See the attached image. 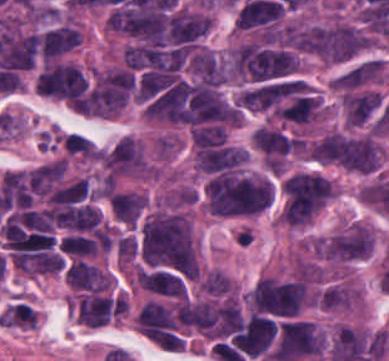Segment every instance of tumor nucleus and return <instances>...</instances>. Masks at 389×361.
<instances>
[{"label": "tumor nucleus", "mask_w": 389, "mask_h": 361, "mask_svg": "<svg viewBox=\"0 0 389 361\" xmlns=\"http://www.w3.org/2000/svg\"><path fill=\"white\" fill-rule=\"evenodd\" d=\"M140 252L148 265L182 275H196L197 264L187 217L150 215L140 227Z\"/></svg>", "instance_id": "1"}, {"label": "tumor nucleus", "mask_w": 389, "mask_h": 361, "mask_svg": "<svg viewBox=\"0 0 389 361\" xmlns=\"http://www.w3.org/2000/svg\"><path fill=\"white\" fill-rule=\"evenodd\" d=\"M270 179L244 170H218L207 179L205 204L216 216L260 213L271 204Z\"/></svg>", "instance_id": "2"}, {"label": "tumor nucleus", "mask_w": 389, "mask_h": 361, "mask_svg": "<svg viewBox=\"0 0 389 361\" xmlns=\"http://www.w3.org/2000/svg\"><path fill=\"white\" fill-rule=\"evenodd\" d=\"M325 151L332 163L361 173H372L382 149L372 134L332 130L325 134Z\"/></svg>", "instance_id": "3"}, {"label": "tumor nucleus", "mask_w": 389, "mask_h": 361, "mask_svg": "<svg viewBox=\"0 0 389 361\" xmlns=\"http://www.w3.org/2000/svg\"><path fill=\"white\" fill-rule=\"evenodd\" d=\"M248 299L255 312L295 315L306 299V290L301 281L262 277Z\"/></svg>", "instance_id": "4"}, {"label": "tumor nucleus", "mask_w": 389, "mask_h": 361, "mask_svg": "<svg viewBox=\"0 0 389 361\" xmlns=\"http://www.w3.org/2000/svg\"><path fill=\"white\" fill-rule=\"evenodd\" d=\"M88 80L81 70L67 63L49 64L37 78L38 94L76 99L84 94Z\"/></svg>", "instance_id": "5"}, {"label": "tumor nucleus", "mask_w": 389, "mask_h": 361, "mask_svg": "<svg viewBox=\"0 0 389 361\" xmlns=\"http://www.w3.org/2000/svg\"><path fill=\"white\" fill-rule=\"evenodd\" d=\"M123 310L124 299L86 294L78 302L77 322L103 327Z\"/></svg>", "instance_id": "6"}, {"label": "tumor nucleus", "mask_w": 389, "mask_h": 361, "mask_svg": "<svg viewBox=\"0 0 389 361\" xmlns=\"http://www.w3.org/2000/svg\"><path fill=\"white\" fill-rule=\"evenodd\" d=\"M246 149L230 146L205 147L196 153L197 168L209 172L233 170L244 162Z\"/></svg>", "instance_id": "7"}, {"label": "tumor nucleus", "mask_w": 389, "mask_h": 361, "mask_svg": "<svg viewBox=\"0 0 389 361\" xmlns=\"http://www.w3.org/2000/svg\"><path fill=\"white\" fill-rule=\"evenodd\" d=\"M79 42V30L68 25H61L47 30L39 39L43 56H58L78 45Z\"/></svg>", "instance_id": "8"}, {"label": "tumor nucleus", "mask_w": 389, "mask_h": 361, "mask_svg": "<svg viewBox=\"0 0 389 361\" xmlns=\"http://www.w3.org/2000/svg\"><path fill=\"white\" fill-rule=\"evenodd\" d=\"M292 139L276 129L257 128L252 135V144L268 155L290 153Z\"/></svg>", "instance_id": "9"}, {"label": "tumor nucleus", "mask_w": 389, "mask_h": 361, "mask_svg": "<svg viewBox=\"0 0 389 361\" xmlns=\"http://www.w3.org/2000/svg\"><path fill=\"white\" fill-rule=\"evenodd\" d=\"M320 105V99L315 95H295L280 108V118L307 123Z\"/></svg>", "instance_id": "10"}, {"label": "tumor nucleus", "mask_w": 389, "mask_h": 361, "mask_svg": "<svg viewBox=\"0 0 389 361\" xmlns=\"http://www.w3.org/2000/svg\"><path fill=\"white\" fill-rule=\"evenodd\" d=\"M122 224H137L146 207V199L133 192L114 190L113 192Z\"/></svg>", "instance_id": "11"}, {"label": "tumor nucleus", "mask_w": 389, "mask_h": 361, "mask_svg": "<svg viewBox=\"0 0 389 361\" xmlns=\"http://www.w3.org/2000/svg\"><path fill=\"white\" fill-rule=\"evenodd\" d=\"M88 198L85 179H79L53 191L49 197V204L70 205Z\"/></svg>", "instance_id": "12"}, {"label": "tumor nucleus", "mask_w": 389, "mask_h": 361, "mask_svg": "<svg viewBox=\"0 0 389 361\" xmlns=\"http://www.w3.org/2000/svg\"><path fill=\"white\" fill-rule=\"evenodd\" d=\"M191 136L195 146L202 148L222 144L226 141V132L219 123L193 127Z\"/></svg>", "instance_id": "13"}, {"label": "tumor nucleus", "mask_w": 389, "mask_h": 361, "mask_svg": "<svg viewBox=\"0 0 389 361\" xmlns=\"http://www.w3.org/2000/svg\"><path fill=\"white\" fill-rule=\"evenodd\" d=\"M230 287L231 283L227 275L222 271H215L208 275L201 289L211 294H222Z\"/></svg>", "instance_id": "14"}]
</instances>
